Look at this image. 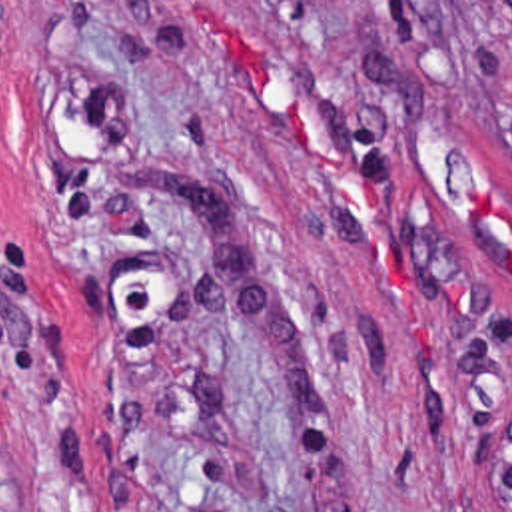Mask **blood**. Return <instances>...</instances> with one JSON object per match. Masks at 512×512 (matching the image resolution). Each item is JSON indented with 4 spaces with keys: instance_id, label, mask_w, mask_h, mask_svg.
I'll return each instance as SVG.
<instances>
[{
    "instance_id": "1",
    "label": "blood",
    "mask_w": 512,
    "mask_h": 512,
    "mask_svg": "<svg viewBox=\"0 0 512 512\" xmlns=\"http://www.w3.org/2000/svg\"><path fill=\"white\" fill-rule=\"evenodd\" d=\"M227 36H229V44H231V54H233V60L249 74V78H261V68L255 64V60L247 54V50L239 44V40L233 36V32L227 28ZM285 126H287V134L291 138V146H293V152L295 156L305 162V164H317V148L313 146V142L309 140V134H307V128L305 124L299 120V116L293 112V110H287V116H285ZM337 162V160H335ZM339 168L343 172H347V168L337 162ZM361 196L369 202L371 208H375V192L367 180V176L363 178V182L359 186H355ZM472 216L480 218V220H488V218H498L504 222L506 226V234H508V256H506V266H508V272L512 274V212H506V210H500L498 204L492 200L488 188L476 192L474 200H472ZM460 279H448L446 287H444V295H446V303L448 305H462L464 303V285L458 283Z\"/></svg>"
}]
</instances>
